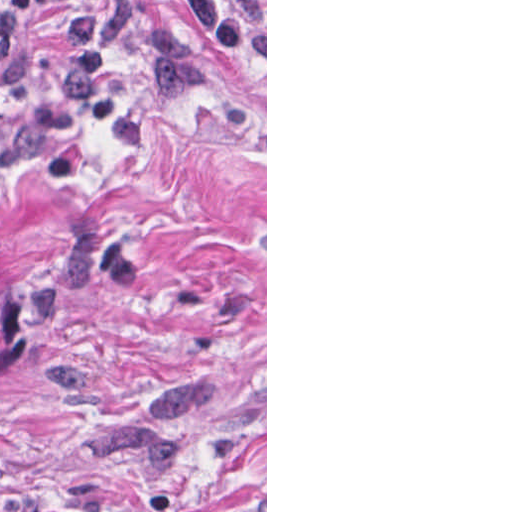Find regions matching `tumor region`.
<instances>
[{"label": "tumor region", "mask_w": 512, "mask_h": 512, "mask_svg": "<svg viewBox=\"0 0 512 512\" xmlns=\"http://www.w3.org/2000/svg\"><path fill=\"white\" fill-rule=\"evenodd\" d=\"M26 311L27 306L9 278L0 270V377L5 344L19 317Z\"/></svg>", "instance_id": "obj_1"}]
</instances>
